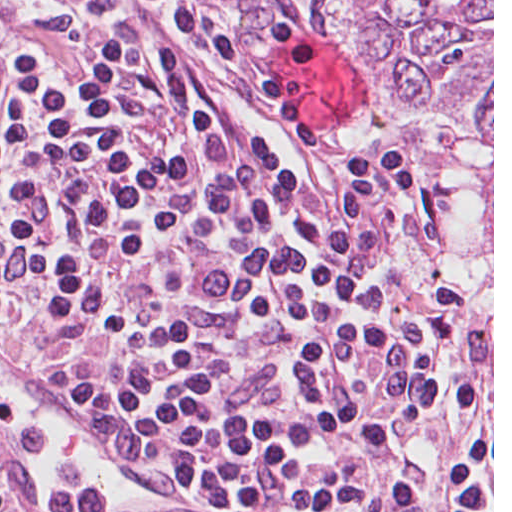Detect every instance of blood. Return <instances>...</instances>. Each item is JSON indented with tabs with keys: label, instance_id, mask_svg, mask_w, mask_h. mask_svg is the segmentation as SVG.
Returning <instances> with one entry per match:
<instances>
[{
	"label": "blood",
	"instance_id": "blood-1",
	"mask_svg": "<svg viewBox=\"0 0 512 512\" xmlns=\"http://www.w3.org/2000/svg\"><path fill=\"white\" fill-rule=\"evenodd\" d=\"M283 83L314 113L318 128H332L352 117V66L324 47L294 42L277 59Z\"/></svg>",
	"mask_w": 512,
	"mask_h": 512
}]
</instances>
